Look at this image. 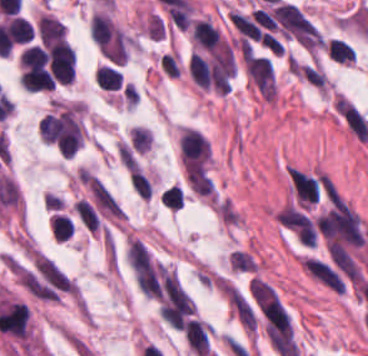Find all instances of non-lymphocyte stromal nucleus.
<instances>
[{
    "mask_svg": "<svg viewBox=\"0 0 368 356\" xmlns=\"http://www.w3.org/2000/svg\"><path fill=\"white\" fill-rule=\"evenodd\" d=\"M244 72L260 94L275 95V83L268 58L250 55L244 63Z\"/></svg>",
    "mask_w": 368,
    "mask_h": 356,
    "instance_id": "1",
    "label": "non-lymphocyte stromal nucleus"
},
{
    "mask_svg": "<svg viewBox=\"0 0 368 356\" xmlns=\"http://www.w3.org/2000/svg\"><path fill=\"white\" fill-rule=\"evenodd\" d=\"M186 177L191 190L197 194L215 199L214 185L206 170L200 164L187 163L185 167Z\"/></svg>",
    "mask_w": 368,
    "mask_h": 356,
    "instance_id": "2",
    "label": "non-lymphocyte stromal nucleus"
},
{
    "mask_svg": "<svg viewBox=\"0 0 368 356\" xmlns=\"http://www.w3.org/2000/svg\"><path fill=\"white\" fill-rule=\"evenodd\" d=\"M230 268L239 272H255L256 262L241 249H234L229 254Z\"/></svg>",
    "mask_w": 368,
    "mask_h": 356,
    "instance_id": "3",
    "label": "non-lymphocyte stromal nucleus"
}]
</instances>
